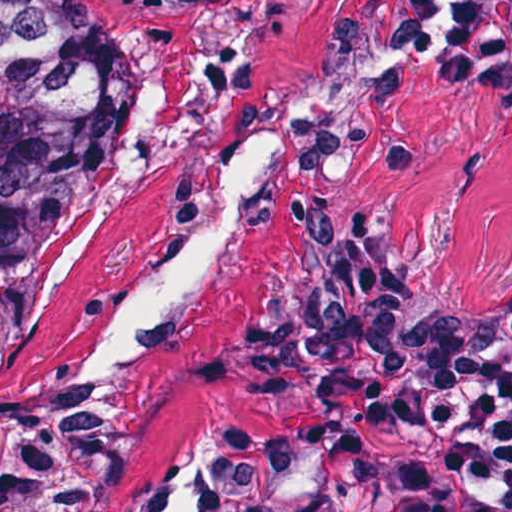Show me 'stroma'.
Returning <instances> with one entry per match:
<instances>
[{"label":"stroma","mask_w":512,"mask_h":512,"mask_svg":"<svg viewBox=\"0 0 512 512\" xmlns=\"http://www.w3.org/2000/svg\"><path fill=\"white\" fill-rule=\"evenodd\" d=\"M512 0H116L127 105L65 218L0 408L110 390L114 512L280 439L305 442L292 315L357 245L431 255L478 302L512 273V80L483 66ZM270 182L198 291L84 382L147 260L210 209L252 143Z\"/></svg>","instance_id":"stroma-1"}]
</instances>
